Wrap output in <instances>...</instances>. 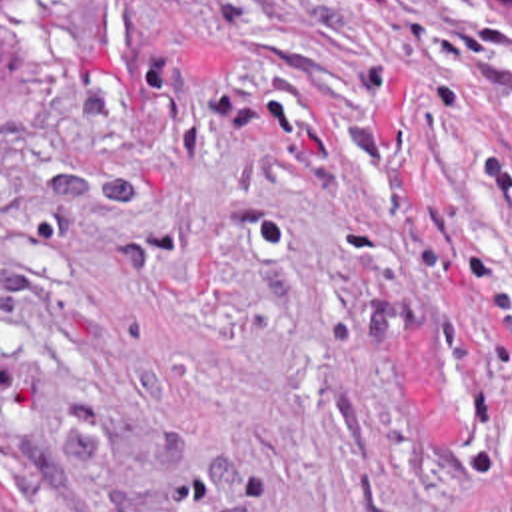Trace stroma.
Segmentation results:
<instances>
[{"label": "stroma", "mask_w": 512, "mask_h": 512, "mask_svg": "<svg viewBox=\"0 0 512 512\" xmlns=\"http://www.w3.org/2000/svg\"><path fill=\"white\" fill-rule=\"evenodd\" d=\"M0 512H512L498 0L0 16Z\"/></svg>", "instance_id": "obj_1"}]
</instances>
